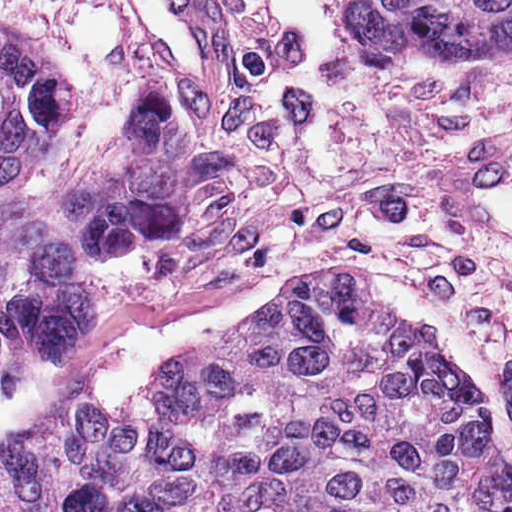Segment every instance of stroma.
<instances>
[{
  "label": "stroma",
  "instance_id": "35a3bbf8",
  "mask_svg": "<svg viewBox=\"0 0 512 512\" xmlns=\"http://www.w3.org/2000/svg\"><path fill=\"white\" fill-rule=\"evenodd\" d=\"M351 4L233 0V89L200 93L149 59L113 0H0L59 52L71 90L17 198L54 209L145 80L181 99L191 151L185 226L90 257V332L15 356L0 454L93 389L115 325L170 316L250 275L283 276L287 297L360 268L441 309L481 355L512 435V233L480 212L512 155V46L467 63L370 58L341 21Z\"/></svg>",
  "mask_w": 512,
  "mask_h": 512
}]
</instances>
